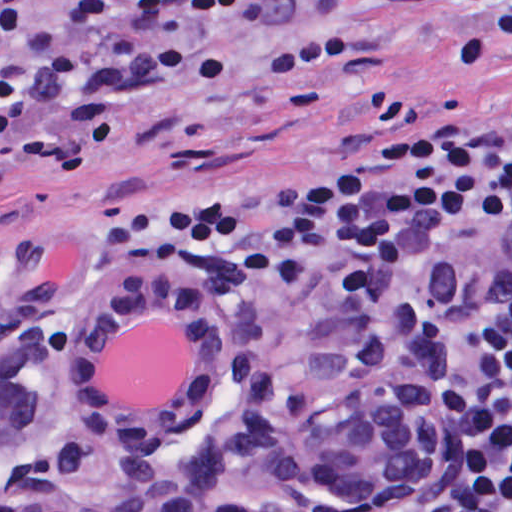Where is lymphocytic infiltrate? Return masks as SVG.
Returning a JSON list of instances; mask_svg holds the SVG:
<instances>
[{"instance_id":"1","label":"lymphocytic infiltrate","mask_w":512,"mask_h":512,"mask_svg":"<svg viewBox=\"0 0 512 512\" xmlns=\"http://www.w3.org/2000/svg\"><path fill=\"white\" fill-rule=\"evenodd\" d=\"M30 0H0V45L26 33ZM311 0H71L0 60V130L68 113L76 163L105 141L113 102L157 109L225 92L259 22ZM381 36L442 64H512V0L445 49L396 0H346ZM135 4L214 17L209 50L121 35L86 71L71 33ZM102 252L148 248L200 282L286 311L371 310L445 361L449 474L465 512H512V110L373 147L239 164L112 203Z\"/></svg>"}]
</instances>
